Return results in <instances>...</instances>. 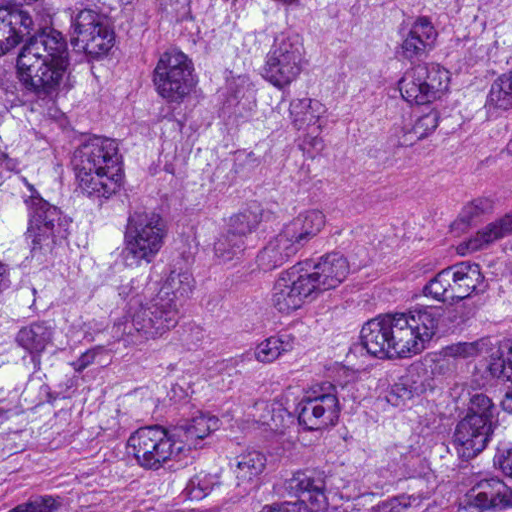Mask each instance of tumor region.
<instances>
[{"mask_svg": "<svg viewBox=\"0 0 512 512\" xmlns=\"http://www.w3.org/2000/svg\"><path fill=\"white\" fill-rule=\"evenodd\" d=\"M512 154V0H0V512H512V247L343 240Z\"/></svg>", "mask_w": 512, "mask_h": 512, "instance_id": "e687c5a6", "label": "tumor region"}]
</instances>
